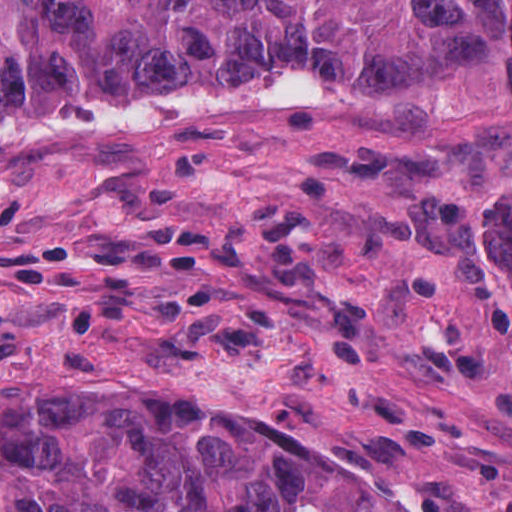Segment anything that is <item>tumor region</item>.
I'll list each match as a JSON object with an SVG mask.
<instances>
[{
  "mask_svg": "<svg viewBox=\"0 0 512 512\" xmlns=\"http://www.w3.org/2000/svg\"><path fill=\"white\" fill-rule=\"evenodd\" d=\"M309 168L346 216L496 195L512 0H0V216ZM0 512H387L160 412L0 400Z\"/></svg>",
  "mask_w": 512,
  "mask_h": 512,
  "instance_id": "tumor-region-1",
  "label": "tumor region"
}]
</instances>
